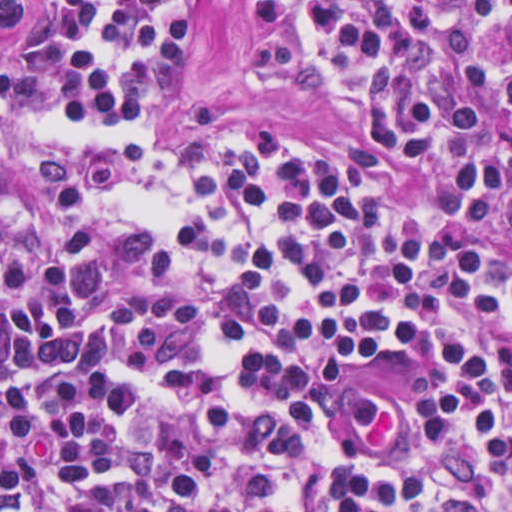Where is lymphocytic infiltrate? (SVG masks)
<instances>
[{
    "instance_id": "f902f5d3",
    "label": "lymphocytic infiltrate",
    "mask_w": 512,
    "mask_h": 512,
    "mask_svg": "<svg viewBox=\"0 0 512 512\" xmlns=\"http://www.w3.org/2000/svg\"><path fill=\"white\" fill-rule=\"evenodd\" d=\"M240 1L347 156L155 145L186 0L0 51V464L66 512H512V0Z\"/></svg>"
}]
</instances>
